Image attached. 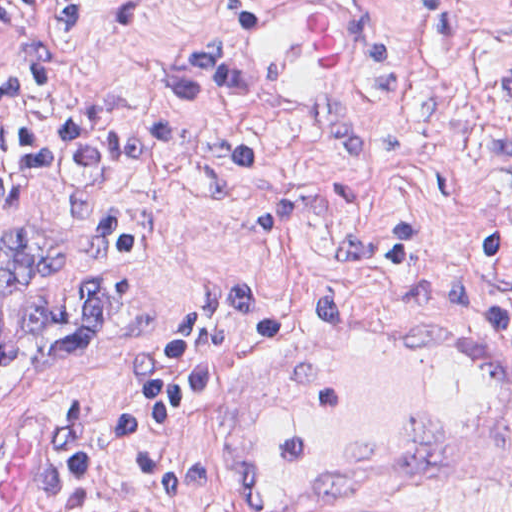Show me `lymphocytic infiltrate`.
Returning a JSON list of instances; mask_svg holds the SVG:
<instances>
[{
	"label": "lymphocytic infiltrate",
	"mask_w": 512,
	"mask_h": 512,
	"mask_svg": "<svg viewBox=\"0 0 512 512\" xmlns=\"http://www.w3.org/2000/svg\"><path fill=\"white\" fill-rule=\"evenodd\" d=\"M57 48L42 40V0H0V24L19 36L0 82V219L25 201L36 166L85 168L105 162L162 171L190 154V133L175 120L140 109L128 86L107 82L97 111L73 110L54 74L89 44L94 0H59ZM512 327V289L499 304ZM284 310L249 292L240 278L207 282L153 340L111 425L129 504L141 510L218 507L224 458L211 449L175 444L191 414L239 376L261 340H278ZM182 427V428H183ZM102 462L79 398L67 396L53 415V459L46 484L24 512L84 508L94 500Z\"/></svg>",
	"instance_id": "lymphocytic-infiltrate-1"
}]
</instances>
